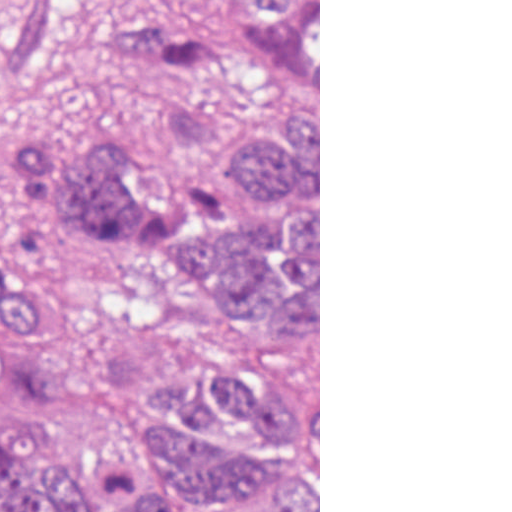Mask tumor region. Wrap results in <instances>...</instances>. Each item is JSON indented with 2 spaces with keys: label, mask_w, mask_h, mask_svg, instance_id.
Listing matches in <instances>:
<instances>
[{
  "label": "tumor region",
  "mask_w": 512,
  "mask_h": 512,
  "mask_svg": "<svg viewBox=\"0 0 512 512\" xmlns=\"http://www.w3.org/2000/svg\"><path fill=\"white\" fill-rule=\"evenodd\" d=\"M73 34L136 66L161 94L160 134L190 197L122 136L73 158L29 114ZM283 103L237 129L232 106ZM319 0H191L104 10L93 0H0V247L44 269L0 284V328L55 304L49 275L131 232L232 299H267L318 332ZM318 512V377L208 347L143 364L138 450L124 477H69L0 407V512Z\"/></svg>",
  "instance_id": "1"
}]
</instances>
